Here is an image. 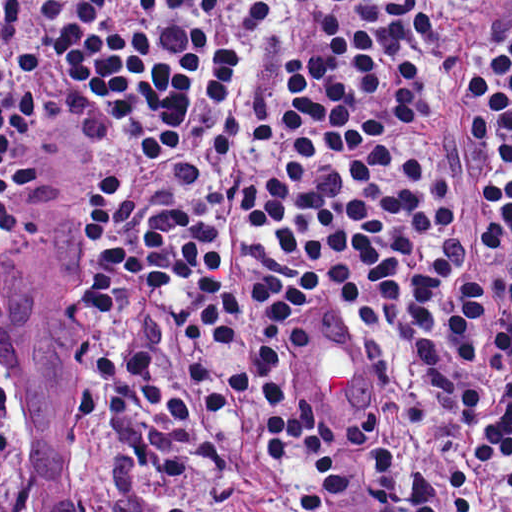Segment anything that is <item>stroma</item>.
<instances>
[{"mask_svg":"<svg viewBox=\"0 0 512 512\" xmlns=\"http://www.w3.org/2000/svg\"><path fill=\"white\" fill-rule=\"evenodd\" d=\"M84 194L85 154L44 125L41 200L27 226L0 222V512H269L250 464L210 497L189 477L128 464L70 404V273ZM361 339L380 376L383 361ZM475 512H512V493Z\"/></svg>","mask_w":512,"mask_h":512,"instance_id":"stroma-1","label":"stroma"}]
</instances>
